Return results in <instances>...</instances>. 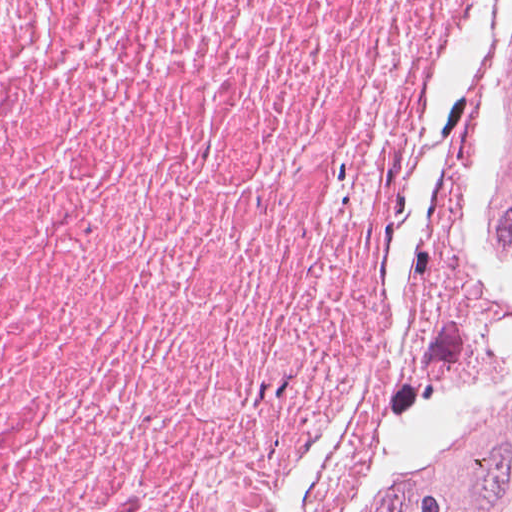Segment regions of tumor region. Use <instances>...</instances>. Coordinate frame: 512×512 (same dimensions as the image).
Here are the masks:
<instances>
[{"instance_id":"obj_1","label":"tumor region","mask_w":512,"mask_h":512,"mask_svg":"<svg viewBox=\"0 0 512 512\" xmlns=\"http://www.w3.org/2000/svg\"><path fill=\"white\" fill-rule=\"evenodd\" d=\"M467 112L512 227V0L489 26ZM395 512H512V346L414 441Z\"/></svg>"}]
</instances>
